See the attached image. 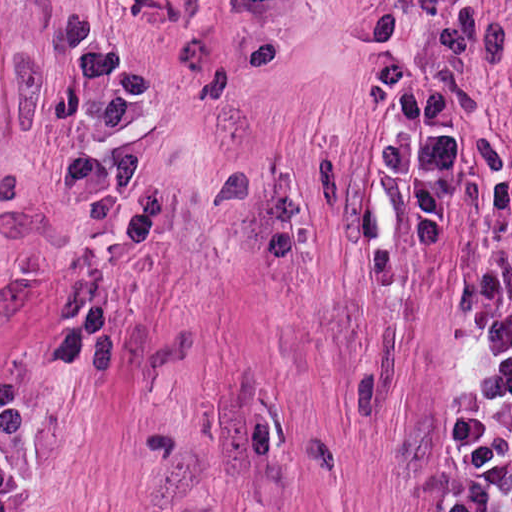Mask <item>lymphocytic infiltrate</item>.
Here are the masks:
<instances>
[{
    "label": "lymphocytic infiltrate",
    "mask_w": 512,
    "mask_h": 512,
    "mask_svg": "<svg viewBox=\"0 0 512 512\" xmlns=\"http://www.w3.org/2000/svg\"><path fill=\"white\" fill-rule=\"evenodd\" d=\"M431 53L411 65L395 0L363 13L365 79L402 111L384 133L377 168L406 213L418 248L440 242L449 211V152L460 125L456 68L491 57L497 32L463 0H414ZM424 512H512V264L470 252L457 320L447 411Z\"/></svg>",
    "instance_id": "1"
}]
</instances>
